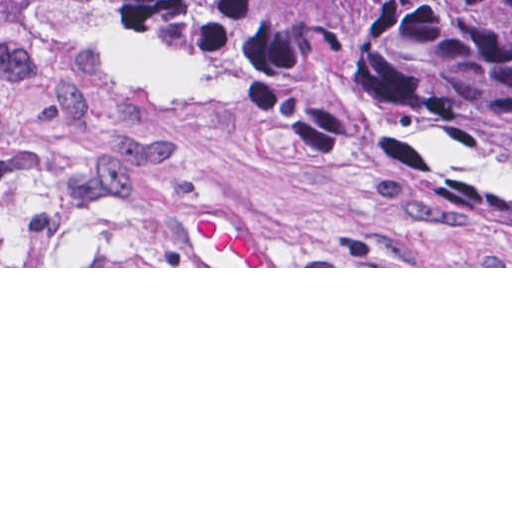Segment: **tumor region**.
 I'll return each mask as SVG.
<instances>
[{"instance_id":"1","label":"tumor region","mask_w":512,"mask_h":512,"mask_svg":"<svg viewBox=\"0 0 512 512\" xmlns=\"http://www.w3.org/2000/svg\"><path fill=\"white\" fill-rule=\"evenodd\" d=\"M0 29L236 92L512 207V0H0Z\"/></svg>"}]
</instances>
